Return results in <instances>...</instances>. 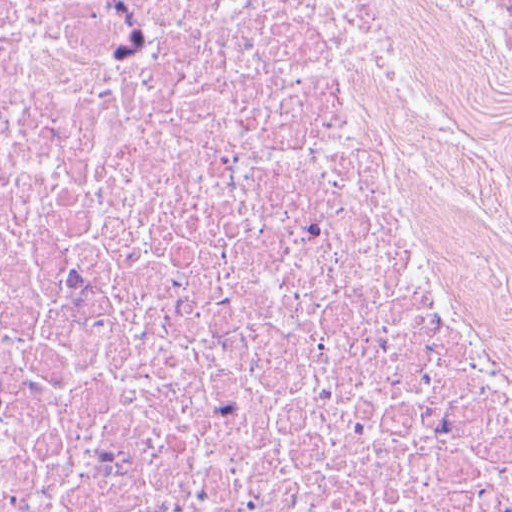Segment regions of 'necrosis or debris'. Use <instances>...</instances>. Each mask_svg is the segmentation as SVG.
Returning <instances> with one entry per match:
<instances>
[{
    "instance_id": "1",
    "label": "necrosis or debris",
    "mask_w": 512,
    "mask_h": 512,
    "mask_svg": "<svg viewBox=\"0 0 512 512\" xmlns=\"http://www.w3.org/2000/svg\"><path fill=\"white\" fill-rule=\"evenodd\" d=\"M0 512H512V0H0Z\"/></svg>"
}]
</instances>
